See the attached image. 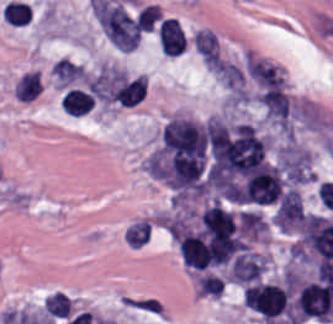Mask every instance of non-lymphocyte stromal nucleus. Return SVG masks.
Here are the masks:
<instances>
[{"label":"non-lymphocyte stromal nucleus","mask_w":333,"mask_h":324,"mask_svg":"<svg viewBox=\"0 0 333 324\" xmlns=\"http://www.w3.org/2000/svg\"><path fill=\"white\" fill-rule=\"evenodd\" d=\"M93 12L105 39L120 49H133L139 39L134 18L118 3L95 0Z\"/></svg>","instance_id":"non-lymphocyte-stromal-nucleus-2"},{"label":"non-lymphocyte stromal nucleus","mask_w":333,"mask_h":324,"mask_svg":"<svg viewBox=\"0 0 333 324\" xmlns=\"http://www.w3.org/2000/svg\"><path fill=\"white\" fill-rule=\"evenodd\" d=\"M140 92L139 76L112 64L85 75L63 97L100 102L131 103Z\"/></svg>","instance_id":"non-lymphocyte-stromal-nucleus-1"},{"label":"non-lymphocyte stromal nucleus","mask_w":333,"mask_h":324,"mask_svg":"<svg viewBox=\"0 0 333 324\" xmlns=\"http://www.w3.org/2000/svg\"><path fill=\"white\" fill-rule=\"evenodd\" d=\"M192 43L204 62H218V42L211 29L199 28L194 33Z\"/></svg>","instance_id":"non-lymphocyte-stromal-nucleus-4"},{"label":"non-lymphocyte stromal nucleus","mask_w":333,"mask_h":324,"mask_svg":"<svg viewBox=\"0 0 333 324\" xmlns=\"http://www.w3.org/2000/svg\"><path fill=\"white\" fill-rule=\"evenodd\" d=\"M161 17L158 6L146 3L137 12L134 20L139 30H152Z\"/></svg>","instance_id":"non-lymphocyte-stromal-nucleus-6"},{"label":"non-lymphocyte stromal nucleus","mask_w":333,"mask_h":324,"mask_svg":"<svg viewBox=\"0 0 333 324\" xmlns=\"http://www.w3.org/2000/svg\"><path fill=\"white\" fill-rule=\"evenodd\" d=\"M41 88L39 75L33 69L22 72L14 86V92L18 100L31 101L38 95Z\"/></svg>","instance_id":"non-lymphocyte-stromal-nucleus-5"},{"label":"non-lymphocyte stromal nucleus","mask_w":333,"mask_h":324,"mask_svg":"<svg viewBox=\"0 0 333 324\" xmlns=\"http://www.w3.org/2000/svg\"><path fill=\"white\" fill-rule=\"evenodd\" d=\"M244 64L254 98L271 107L286 97L280 68L247 54Z\"/></svg>","instance_id":"non-lymphocyte-stromal-nucleus-3"}]
</instances>
